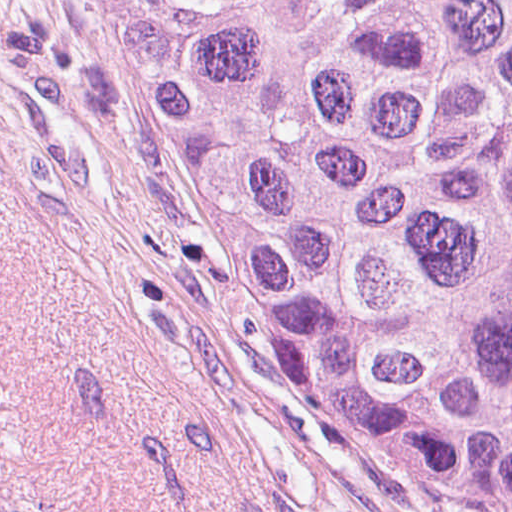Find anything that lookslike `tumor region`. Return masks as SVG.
I'll return each mask as SVG.
<instances>
[{
	"label": "tumor region",
	"mask_w": 512,
	"mask_h": 512,
	"mask_svg": "<svg viewBox=\"0 0 512 512\" xmlns=\"http://www.w3.org/2000/svg\"><path fill=\"white\" fill-rule=\"evenodd\" d=\"M137 141L328 408L512 512V0H88Z\"/></svg>",
	"instance_id": "e687c5a6"
}]
</instances>
